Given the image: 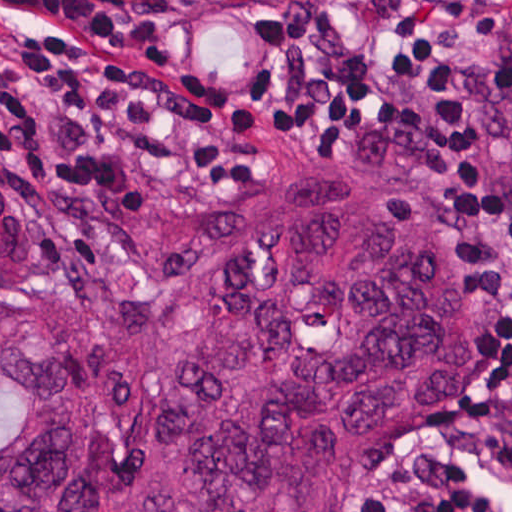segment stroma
<instances>
[{
	"mask_svg": "<svg viewBox=\"0 0 512 512\" xmlns=\"http://www.w3.org/2000/svg\"><path fill=\"white\" fill-rule=\"evenodd\" d=\"M165 13H246L299 27H337L364 35H414L428 25L449 27L472 92L477 127L489 165L496 227L512 276V162L489 96L493 29L512 0H379L346 12H281L270 0H132ZM210 129L244 145L259 162L248 181L225 194H186L129 204H103L65 185L32 184L5 170L30 196L43 226V273L54 283H94L122 293H155L158 280L132 246L117 244L112 228L125 220H210L235 213L279 182L329 173L366 188H388L454 225L469 241L476 263V387L464 410L378 460L347 495L341 512H367L388 484L419 472L477 441L512 414V386L493 383L492 296L486 256L475 227L437 192L352 148H289L270 135L239 129L221 114L176 97L171 100ZM0 293H8L0 291Z\"/></svg>",
	"mask_w": 512,
	"mask_h": 512,
	"instance_id": "1",
	"label": "stroma"
}]
</instances>
